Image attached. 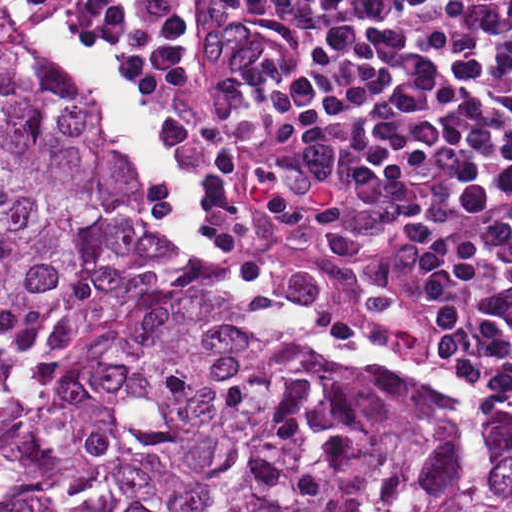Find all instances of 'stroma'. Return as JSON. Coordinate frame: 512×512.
I'll return each mask as SVG.
<instances>
[{
  "label": "stroma",
  "mask_w": 512,
  "mask_h": 512,
  "mask_svg": "<svg viewBox=\"0 0 512 512\" xmlns=\"http://www.w3.org/2000/svg\"><path fill=\"white\" fill-rule=\"evenodd\" d=\"M8 1H67L69 9L71 11L74 26L79 32L87 38V40L96 49L98 54L101 56L108 69L112 73L113 77L122 83L127 90H129L136 98L143 114L147 118L149 124L159 137V139L167 146V148L175 155V157L181 163L184 172L198 192L200 205L202 209V230L205 235L206 241L213 251L220 257V259L232 269L238 271L244 279L255 286H258L269 293L275 295L277 298L292 306L296 310L318 316L320 318L328 320L342 333L352 339L354 342L364 346V349L358 355H339L331 347L325 345L319 339L301 330L297 326L282 322L276 318L255 310L247 306L259 317L269 322L277 331L285 336L287 339L292 341L298 346H302L310 351L329 356L335 360H338L344 364L367 367L373 369H395L400 371L411 372L419 375L428 377L448 388L455 389L458 391L479 395L490 402L512 409V397L489 392L477 387H473L464 384L449 376L447 368L445 370L430 368L426 364L422 363L418 359L414 358L404 349L399 346L392 345L383 340L377 339L370 335L359 332L352 327L308 306L293 300L276 290L270 288L259 279L250 274L247 270L240 267L234 261H232L218 246L210 222L206 215L205 209L202 203V194L199 189L198 183L194 176L193 170L189 163L186 152L178 136L171 129L170 125L166 121L165 117L161 115L158 110L149 102L146 96L141 90L132 85L126 80L122 73L101 53L100 49L96 45L93 38L88 33L87 29L82 26L78 21L73 18L75 2L76 1H512V0H0V6L6 14L8 20L19 32L22 38L28 43L34 56L41 61L40 57L36 53L32 44L28 40L23 30L22 24L12 9ZM42 62V61H41ZM43 63V62H42ZM50 71L51 76L56 81L57 85L61 89L62 93L69 100V102L82 114L87 120L94 126L98 133L112 148L118 158L126 167L130 176L134 180L141 196L144 201L145 207L151 217L154 219L158 231L160 233L163 251L175 262L180 265L196 270L202 273L207 278L211 279L224 293H226L232 299L242 302L234 294H232L223 279L211 268L204 265L202 262L197 260L188 252L184 251L180 247L176 246L170 230L164 220L155 193L152 189L149 179L143 175L136 167L131 156L127 153L123 145L118 141L108 125L104 121L103 117L99 115L87 102L83 95L74 90L61 76L50 69L45 63H43ZM245 304V303H244ZM424 351V350H423ZM432 357L445 361L446 365L452 362V359L446 358L440 355H436L427 351H424Z\"/></svg>",
  "instance_id": "stroma-1"
}]
</instances>
